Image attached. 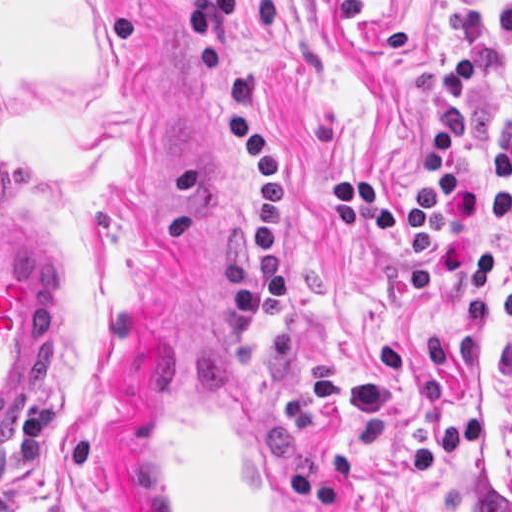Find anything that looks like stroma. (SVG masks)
I'll use <instances>...</instances> for the list:
<instances>
[{
  "label": "stroma",
  "instance_id": "35a3bbf8",
  "mask_svg": "<svg viewBox=\"0 0 512 512\" xmlns=\"http://www.w3.org/2000/svg\"><path fill=\"white\" fill-rule=\"evenodd\" d=\"M470 5L494 34L496 0H233L234 104L293 177L297 328L276 339L191 0H0V215L65 290L39 395L0 442V511L138 512L143 371L204 349L255 382L320 512H512V222L477 234L502 244L486 327L451 277L423 309L389 238L326 222L352 172L417 203L432 76L468 52ZM465 105L479 177L512 49Z\"/></svg>",
  "mask_w": 512,
  "mask_h": 512
}]
</instances>
